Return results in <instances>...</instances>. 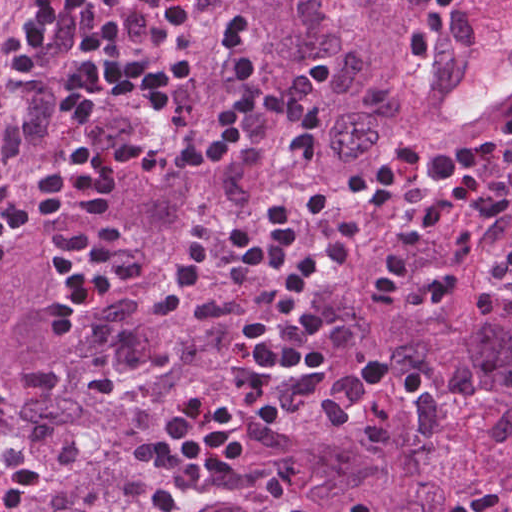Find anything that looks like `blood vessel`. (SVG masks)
Masks as SVG:
<instances>
[{
    "mask_svg": "<svg viewBox=\"0 0 512 512\" xmlns=\"http://www.w3.org/2000/svg\"><path fill=\"white\" fill-rule=\"evenodd\" d=\"M423 135L452 146L512 109V0H477L454 14L429 68Z\"/></svg>",
    "mask_w": 512,
    "mask_h": 512,
    "instance_id": "8fb6f2fc",
    "label": "blood vessel"
}]
</instances>
